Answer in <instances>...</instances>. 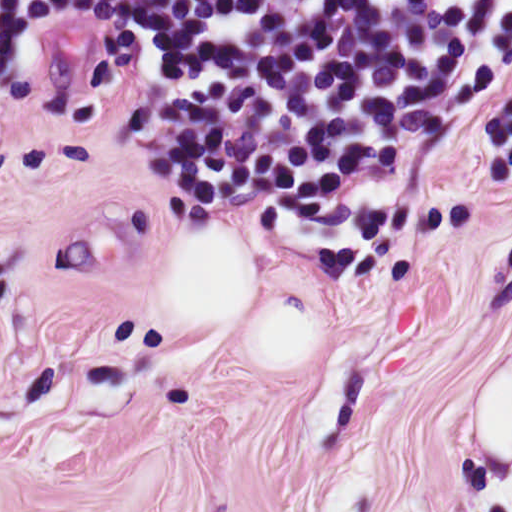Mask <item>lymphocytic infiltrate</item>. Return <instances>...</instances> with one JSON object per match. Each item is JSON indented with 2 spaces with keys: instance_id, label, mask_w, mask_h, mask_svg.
<instances>
[{
  "instance_id": "1",
  "label": "lymphocytic infiltrate",
  "mask_w": 512,
  "mask_h": 512,
  "mask_svg": "<svg viewBox=\"0 0 512 512\" xmlns=\"http://www.w3.org/2000/svg\"><path fill=\"white\" fill-rule=\"evenodd\" d=\"M144 50V148L203 218L477 96L512 0H0V74L76 25Z\"/></svg>"
}]
</instances>
